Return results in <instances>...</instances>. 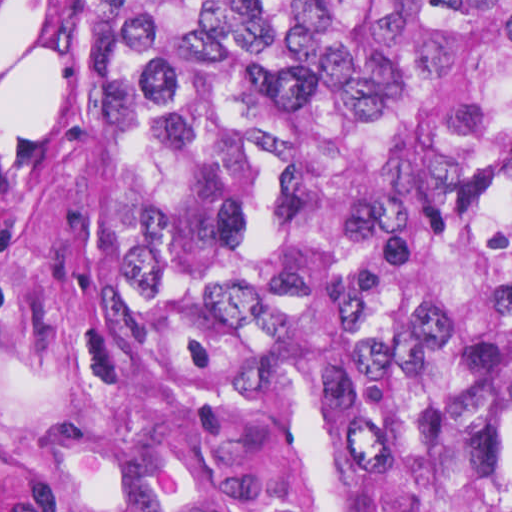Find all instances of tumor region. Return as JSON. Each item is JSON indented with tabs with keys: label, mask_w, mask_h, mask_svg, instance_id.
Here are the masks:
<instances>
[{
	"label": "tumor region",
	"mask_w": 512,
	"mask_h": 512,
	"mask_svg": "<svg viewBox=\"0 0 512 512\" xmlns=\"http://www.w3.org/2000/svg\"><path fill=\"white\" fill-rule=\"evenodd\" d=\"M70 81L125 351L331 512H512V1H89Z\"/></svg>",
	"instance_id": "e687c5a6"
}]
</instances>
